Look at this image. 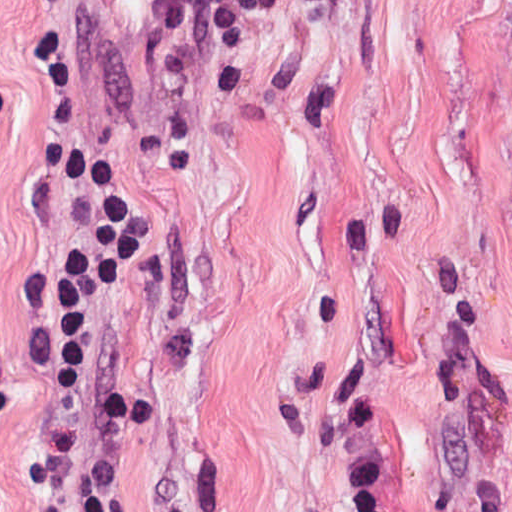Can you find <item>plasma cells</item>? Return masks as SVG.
Segmentation results:
<instances>
[{"label": "plasma cells", "instance_id": "plasma-cells-1", "mask_svg": "<svg viewBox=\"0 0 512 512\" xmlns=\"http://www.w3.org/2000/svg\"><path fill=\"white\" fill-rule=\"evenodd\" d=\"M293 1L331 8L340 0H155L141 20L143 72L154 88H170L192 60L205 24L214 33L220 87L229 95H244L251 80L252 29Z\"/></svg>", "mask_w": 512, "mask_h": 512}]
</instances>
